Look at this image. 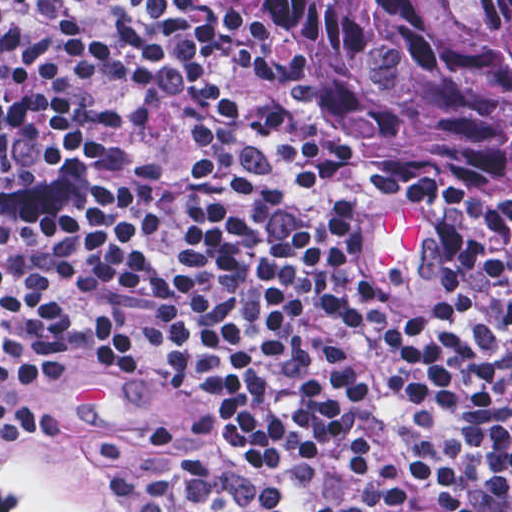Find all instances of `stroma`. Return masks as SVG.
I'll list each match as a JSON object with an SVG mask.
<instances>
[{
    "label": "stroma",
    "instance_id": "obj_1",
    "mask_svg": "<svg viewBox=\"0 0 512 512\" xmlns=\"http://www.w3.org/2000/svg\"><path fill=\"white\" fill-rule=\"evenodd\" d=\"M216 423L206 402L119 386H47L31 402V424L19 441L0 444L83 512H116L104 480L117 462ZM0 512L53 511L31 506L0 480Z\"/></svg>",
    "mask_w": 512,
    "mask_h": 512
}]
</instances>
